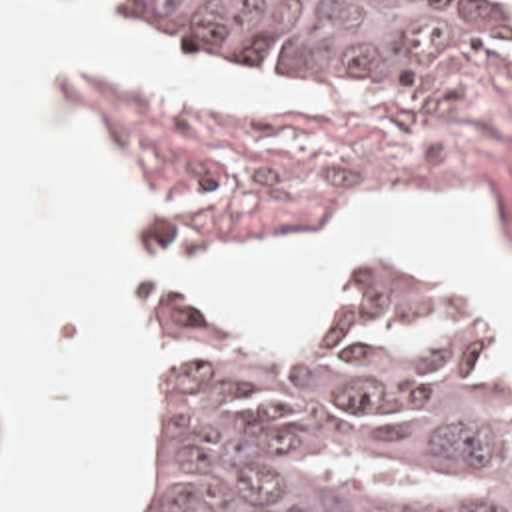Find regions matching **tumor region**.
<instances>
[{"label": "tumor region", "instance_id": "obj_1", "mask_svg": "<svg viewBox=\"0 0 512 512\" xmlns=\"http://www.w3.org/2000/svg\"><path fill=\"white\" fill-rule=\"evenodd\" d=\"M322 74H448L512 48V0H136ZM120 512H512V398L488 330L386 270L284 350L168 340L154 476Z\"/></svg>", "mask_w": 512, "mask_h": 512}]
</instances>
